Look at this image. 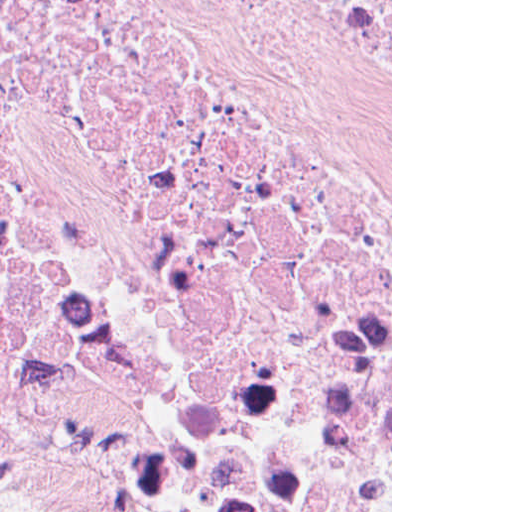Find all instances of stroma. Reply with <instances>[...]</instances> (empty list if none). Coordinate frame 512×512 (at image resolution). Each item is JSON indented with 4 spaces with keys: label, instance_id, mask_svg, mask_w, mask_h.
<instances>
[{
    "label": "stroma",
    "instance_id": "obj_1",
    "mask_svg": "<svg viewBox=\"0 0 512 512\" xmlns=\"http://www.w3.org/2000/svg\"><path fill=\"white\" fill-rule=\"evenodd\" d=\"M0 512H145L118 500L59 489L0 465ZM391 512H392V0H391Z\"/></svg>",
    "mask_w": 512,
    "mask_h": 512
}]
</instances>
